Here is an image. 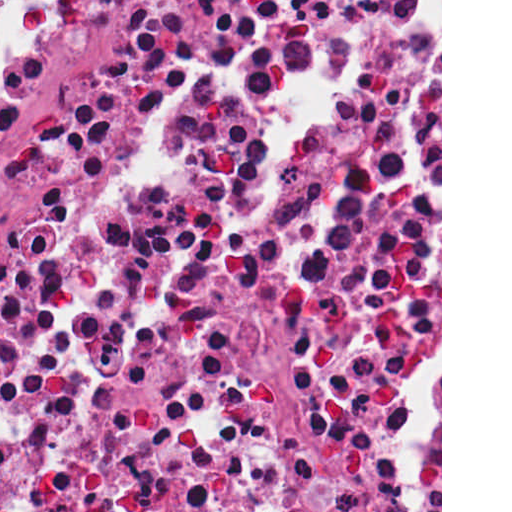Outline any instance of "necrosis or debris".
I'll list each match as a JSON object with an SVG mask.
<instances>
[{"instance_id":"1","label":"necrosis or debris","mask_w":512,"mask_h":512,"mask_svg":"<svg viewBox=\"0 0 512 512\" xmlns=\"http://www.w3.org/2000/svg\"><path fill=\"white\" fill-rule=\"evenodd\" d=\"M0 512H268L40 0H0Z\"/></svg>"}]
</instances>
